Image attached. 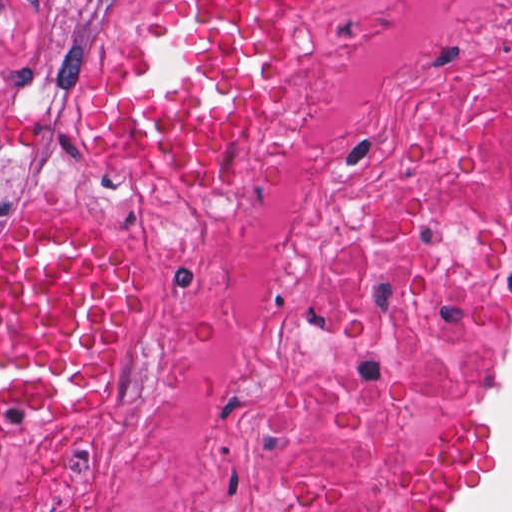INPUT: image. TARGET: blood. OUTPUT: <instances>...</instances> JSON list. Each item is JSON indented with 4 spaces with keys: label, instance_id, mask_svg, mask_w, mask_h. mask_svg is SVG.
Returning <instances> with one entry per match:
<instances>
[{
    "label": "blood",
    "instance_id": "blood-1",
    "mask_svg": "<svg viewBox=\"0 0 512 512\" xmlns=\"http://www.w3.org/2000/svg\"><path fill=\"white\" fill-rule=\"evenodd\" d=\"M306 0H178L99 111L116 152L214 173L269 88L272 35ZM145 292L137 263L80 230L0 237V417H68L100 388Z\"/></svg>",
    "mask_w": 512,
    "mask_h": 512
}]
</instances>
